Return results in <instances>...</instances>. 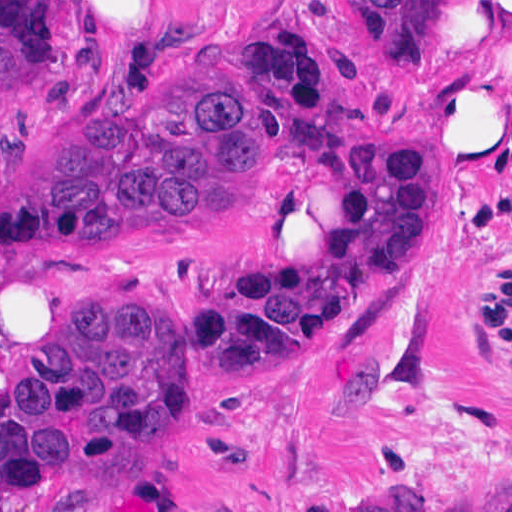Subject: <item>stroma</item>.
I'll use <instances>...</instances> for the list:
<instances>
[{"label": "stroma", "mask_w": 512, "mask_h": 512, "mask_svg": "<svg viewBox=\"0 0 512 512\" xmlns=\"http://www.w3.org/2000/svg\"><path fill=\"white\" fill-rule=\"evenodd\" d=\"M466 0L436 58L388 35L377 0H56V53L0 83V197L103 103L138 111L171 79L237 66L285 133L331 127L424 141L484 37ZM236 26V27H235ZM424 182L446 203L428 264L257 352L246 382L210 345L202 295L269 245L325 251L344 195L284 162L241 192L231 224L166 227L87 252L0 253V403L85 309L163 296L188 439L167 456L102 460L0 512H316L417 487L428 512H512V103L508 134L439 152ZM460 210V211H459Z\"/></svg>", "instance_id": "35a3bbf8"}]
</instances>
